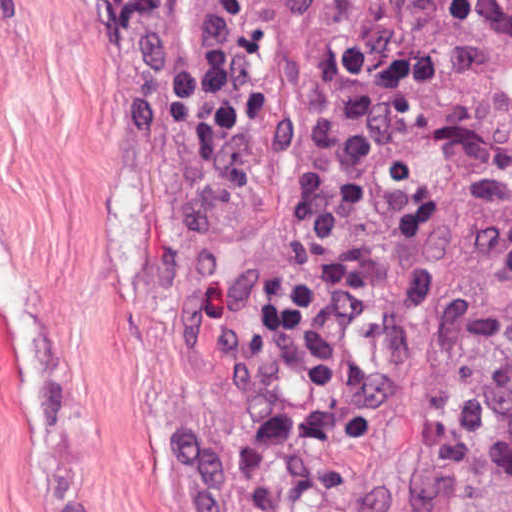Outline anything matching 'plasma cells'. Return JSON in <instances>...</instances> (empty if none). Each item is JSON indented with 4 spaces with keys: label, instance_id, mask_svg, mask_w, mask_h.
<instances>
[{
    "label": "plasma cells",
    "instance_id": "plasma-cells-1",
    "mask_svg": "<svg viewBox=\"0 0 512 512\" xmlns=\"http://www.w3.org/2000/svg\"><path fill=\"white\" fill-rule=\"evenodd\" d=\"M501 150L512 165V106L501 130ZM488 283L504 315L500 332L470 338L464 354L512 384V232L488 263Z\"/></svg>",
    "mask_w": 512,
    "mask_h": 512
}]
</instances>
